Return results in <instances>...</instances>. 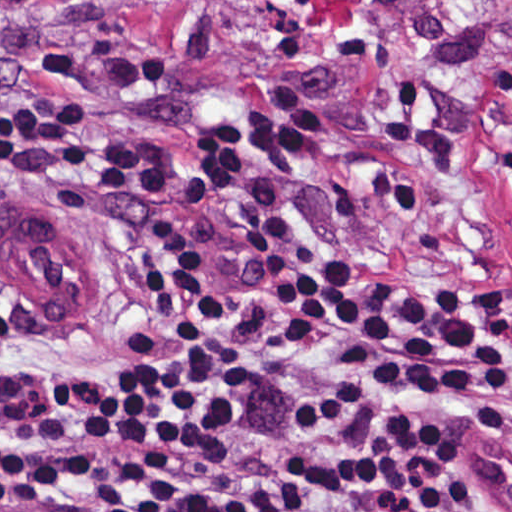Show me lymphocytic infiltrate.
<instances>
[{
	"label": "lymphocytic infiltrate",
	"instance_id": "obj_1",
	"mask_svg": "<svg viewBox=\"0 0 512 512\" xmlns=\"http://www.w3.org/2000/svg\"><path fill=\"white\" fill-rule=\"evenodd\" d=\"M182 177L111 102L0 85V191L154 193ZM224 215L315 363L293 391V467L323 512H512V484L442 504L448 459L512 379L505 313L354 272L282 193L219 176ZM249 440L244 357L207 241L126 249L93 364L0 357V482L28 512H289L272 462L211 478Z\"/></svg>",
	"mask_w": 512,
	"mask_h": 512
}]
</instances>
